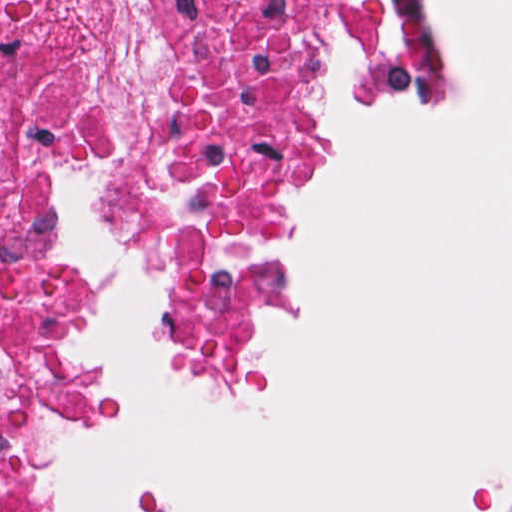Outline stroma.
Returning a JSON list of instances; mask_svg holds the SVG:
<instances>
[{"instance_id": "obj_1", "label": "stroma", "mask_w": 512, "mask_h": 512, "mask_svg": "<svg viewBox=\"0 0 512 512\" xmlns=\"http://www.w3.org/2000/svg\"><path fill=\"white\" fill-rule=\"evenodd\" d=\"M202 1H380L405 10L414 37L405 82L393 97L375 82L370 43L309 40L293 47L304 97L300 138L282 172L254 296V338L247 373L233 384L210 380L195 364L178 327V303L162 269L145 257L121 216L117 175L104 163L84 165L50 180V204L59 252L70 179L91 183L109 239L126 262L146 270L154 289L158 331L176 373L208 404L257 409L272 394L276 331L272 313L291 307V275L284 245L288 222L305 206L291 194L331 172V129L321 92L307 73L344 53L367 115L403 96L427 104L442 120L462 116L458 57L442 46V20L434 1L512 0H0V75L38 57H64L81 66L107 108L121 118H144L161 108L174 86V60L182 42L201 32ZM217 25L203 31L206 37ZM73 276V275H72ZM78 287V286H77ZM79 289L82 385L74 403L43 422L33 455V477L62 512H93L50 477V452L66 436H114L118 415L106 377L90 362L98 316ZM487 512H512V481L487 504Z\"/></svg>"}]
</instances>
